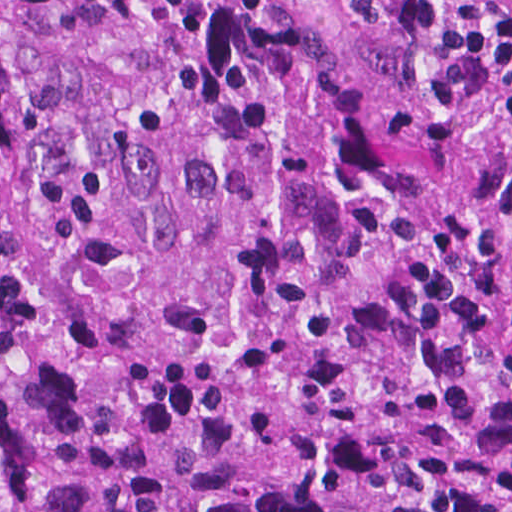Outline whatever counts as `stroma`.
Returning a JSON list of instances; mask_svg holds the SVG:
<instances>
[{
  "instance_id": "1",
  "label": "stroma",
  "mask_w": 512,
  "mask_h": 512,
  "mask_svg": "<svg viewBox=\"0 0 512 512\" xmlns=\"http://www.w3.org/2000/svg\"><path fill=\"white\" fill-rule=\"evenodd\" d=\"M307 3L332 32L345 64L386 110L399 145L435 167L475 216L512 233V171L497 167L455 125L441 97L451 4L442 6L434 29L408 32L366 22L354 0Z\"/></svg>"
}]
</instances>
